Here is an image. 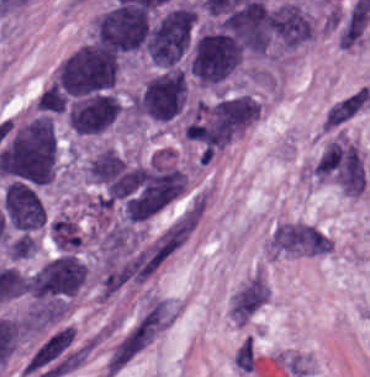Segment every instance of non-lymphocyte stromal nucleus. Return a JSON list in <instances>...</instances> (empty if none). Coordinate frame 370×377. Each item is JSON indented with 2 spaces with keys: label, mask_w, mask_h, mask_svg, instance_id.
<instances>
[{
  "label": "non-lymphocyte stromal nucleus",
  "mask_w": 370,
  "mask_h": 377,
  "mask_svg": "<svg viewBox=\"0 0 370 377\" xmlns=\"http://www.w3.org/2000/svg\"><path fill=\"white\" fill-rule=\"evenodd\" d=\"M177 302L157 294L140 300L108 351L105 362L106 376H115L157 338L176 318Z\"/></svg>",
  "instance_id": "non-lymphocyte-stromal-nucleus-1"
},
{
  "label": "non-lymphocyte stromal nucleus",
  "mask_w": 370,
  "mask_h": 377,
  "mask_svg": "<svg viewBox=\"0 0 370 377\" xmlns=\"http://www.w3.org/2000/svg\"><path fill=\"white\" fill-rule=\"evenodd\" d=\"M270 244L275 251L304 256H322L332 247L330 239L314 226L295 222L276 226Z\"/></svg>",
  "instance_id": "non-lymphocyte-stromal-nucleus-2"
},
{
  "label": "non-lymphocyte stromal nucleus",
  "mask_w": 370,
  "mask_h": 377,
  "mask_svg": "<svg viewBox=\"0 0 370 377\" xmlns=\"http://www.w3.org/2000/svg\"><path fill=\"white\" fill-rule=\"evenodd\" d=\"M272 288L267 277L257 267L232 291L228 302L231 323L246 326L268 302Z\"/></svg>",
  "instance_id": "non-lymphocyte-stromal-nucleus-3"
},
{
  "label": "non-lymphocyte stromal nucleus",
  "mask_w": 370,
  "mask_h": 377,
  "mask_svg": "<svg viewBox=\"0 0 370 377\" xmlns=\"http://www.w3.org/2000/svg\"><path fill=\"white\" fill-rule=\"evenodd\" d=\"M362 94L354 93L333 104L324 118V128H331L351 118L357 109Z\"/></svg>",
  "instance_id": "non-lymphocyte-stromal-nucleus-4"
}]
</instances>
